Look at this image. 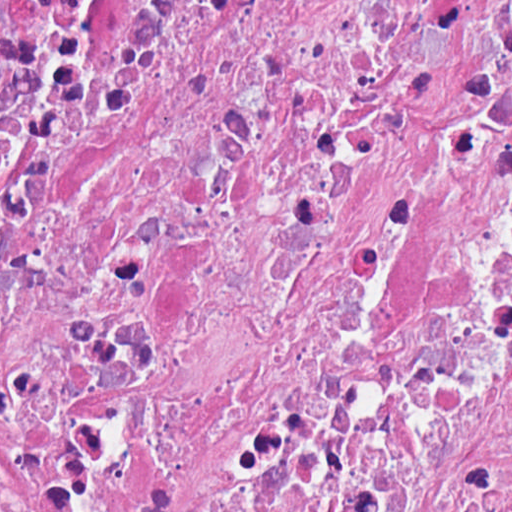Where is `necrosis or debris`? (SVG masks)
I'll list each match as a JSON object with an SVG mask.
<instances>
[{
  "label": "necrosis or debris",
  "mask_w": 512,
  "mask_h": 512,
  "mask_svg": "<svg viewBox=\"0 0 512 512\" xmlns=\"http://www.w3.org/2000/svg\"><path fill=\"white\" fill-rule=\"evenodd\" d=\"M0 512H512V0H0Z\"/></svg>",
  "instance_id": "4bbe7bcc"
}]
</instances>
